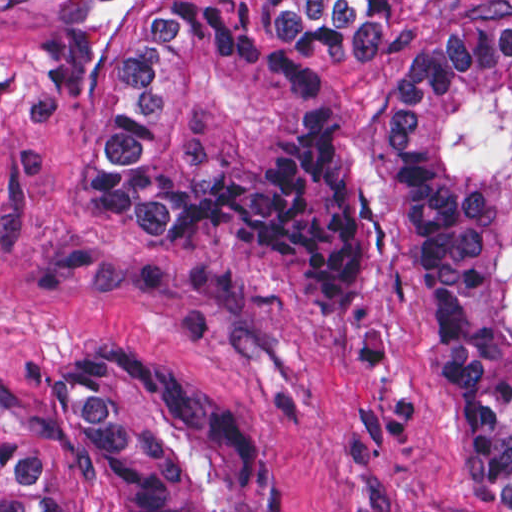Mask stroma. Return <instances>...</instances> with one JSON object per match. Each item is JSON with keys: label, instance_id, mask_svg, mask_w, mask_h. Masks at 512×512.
<instances>
[{"label": "stroma", "instance_id": "stroma-1", "mask_svg": "<svg viewBox=\"0 0 512 512\" xmlns=\"http://www.w3.org/2000/svg\"><path fill=\"white\" fill-rule=\"evenodd\" d=\"M57 1L512 0H0V512L1 424H34L37 385L103 341L161 344L245 412L283 490L247 512H488L445 462L430 305L386 160L398 67L432 31L424 11L393 2L400 47L374 72L320 61L367 304L358 319H318L253 234L151 241L77 199L74 141L87 109L40 63Z\"/></svg>", "mask_w": 512, "mask_h": 512}]
</instances>
